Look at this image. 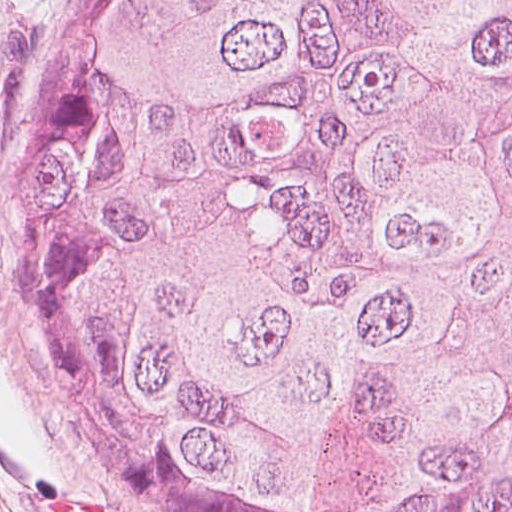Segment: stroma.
I'll return each instance as SVG.
<instances>
[{
  "mask_svg": "<svg viewBox=\"0 0 512 512\" xmlns=\"http://www.w3.org/2000/svg\"><path fill=\"white\" fill-rule=\"evenodd\" d=\"M68 0H0V212L17 128ZM0 512H162L74 451L40 406L15 336L0 243Z\"/></svg>",
  "mask_w": 512,
  "mask_h": 512,
  "instance_id": "1",
  "label": "stroma"
}]
</instances>
